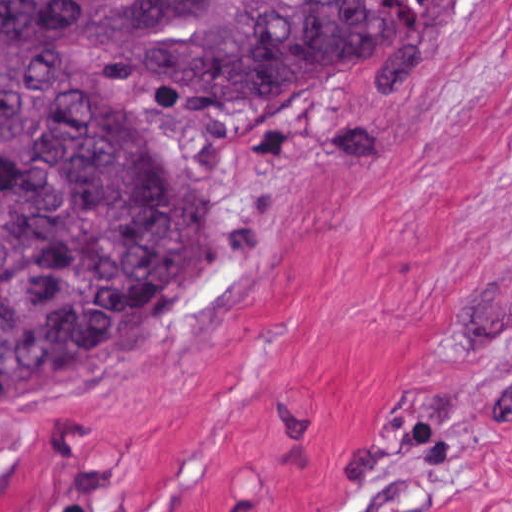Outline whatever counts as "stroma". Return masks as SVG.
I'll list each match as a JSON object with an SVG mask.
<instances>
[{
  "instance_id": "35a3bbf8",
  "label": "stroma",
  "mask_w": 512,
  "mask_h": 512,
  "mask_svg": "<svg viewBox=\"0 0 512 512\" xmlns=\"http://www.w3.org/2000/svg\"><path fill=\"white\" fill-rule=\"evenodd\" d=\"M191 223L145 379L0 417V512H512V0L396 62L94 100Z\"/></svg>"
}]
</instances>
